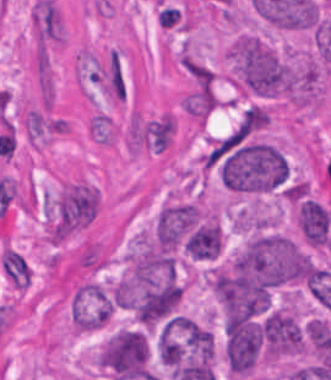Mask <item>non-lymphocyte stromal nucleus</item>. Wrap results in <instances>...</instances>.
Returning a JSON list of instances; mask_svg holds the SVG:
<instances>
[{
    "instance_id": "non-lymphocyte-stromal-nucleus-1",
    "label": "non-lymphocyte stromal nucleus",
    "mask_w": 331,
    "mask_h": 380,
    "mask_svg": "<svg viewBox=\"0 0 331 380\" xmlns=\"http://www.w3.org/2000/svg\"><path fill=\"white\" fill-rule=\"evenodd\" d=\"M1 267L16 288H26L31 282V270L23 256L4 246L1 252Z\"/></svg>"
}]
</instances>
